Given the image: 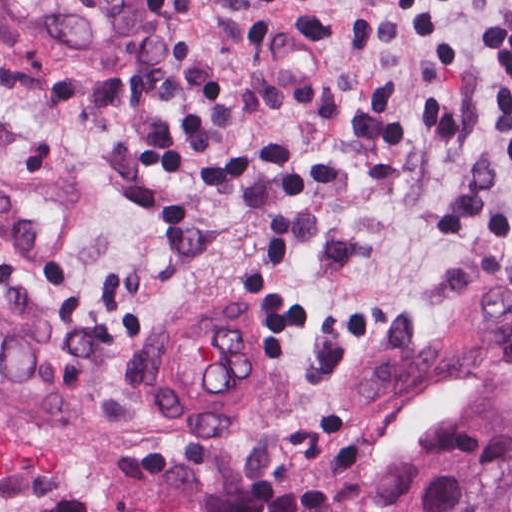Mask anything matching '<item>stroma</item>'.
<instances>
[{"instance_id": "obj_1", "label": "stroma", "mask_w": 512, "mask_h": 512, "mask_svg": "<svg viewBox=\"0 0 512 512\" xmlns=\"http://www.w3.org/2000/svg\"><path fill=\"white\" fill-rule=\"evenodd\" d=\"M512 0H158L130 76L0 9V512H512ZM264 317L225 434L156 419L165 317Z\"/></svg>"}]
</instances>
